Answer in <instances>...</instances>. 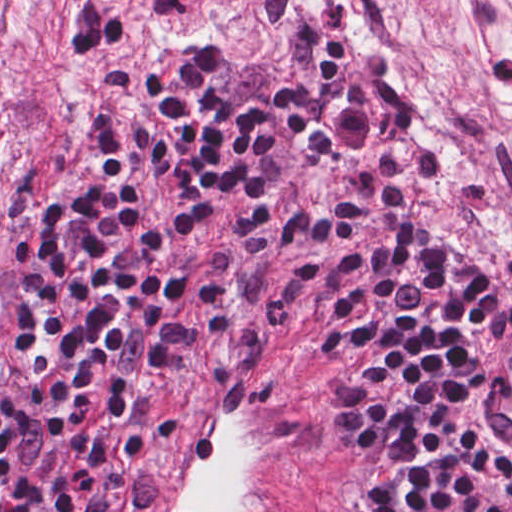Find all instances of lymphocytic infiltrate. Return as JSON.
<instances>
[{"instance_id":"lymphocytic-infiltrate-1","label":"lymphocytic infiltrate","mask_w":512,"mask_h":512,"mask_svg":"<svg viewBox=\"0 0 512 512\" xmlns=\"http://www.w3.org/2000/svg\"><path fill=\"white\" fill-rule=\"evenodd\" d=\"M220 301L316 364L345 512H512V449L474 420L512 341V271L342 106L227 39L86 119L17 204L0 512H105L106 474Z\"/></svg>"}]
</instances>
